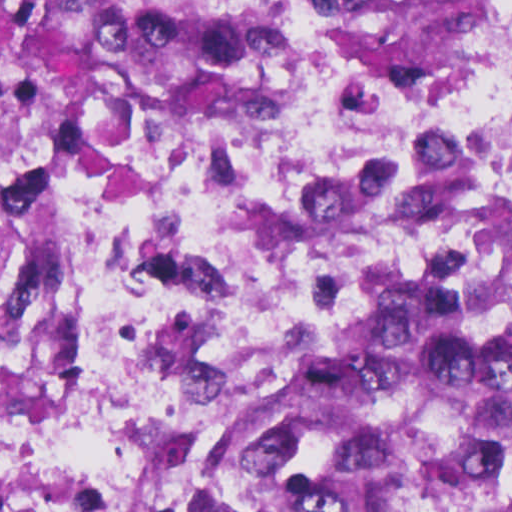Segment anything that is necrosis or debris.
I'll return each instance as SVG.
<instances>
[{
	"label": "necrosis or debris",
	"instance_id": "obj_1",
	"mask_svg": "<svg viewBox=\"0 0 512 512\" xmlns=\"http://www.w3.org/2000/svg\"><path fill=\"white\" fill-rule=\"evenodd\" d=\"M340 0H265L268 71L88 104L50 175L35 391L9 325L28 232L32 67L0 26V512H117L156 476L199 369L238 336L391 269L512 190V44L409 94L362 84ZM512 433V361L498 389ZM107 470V471H106Z\"/></svg>",
	"mask_w": 512,
	"mask_h": 512
}]
</instances>
